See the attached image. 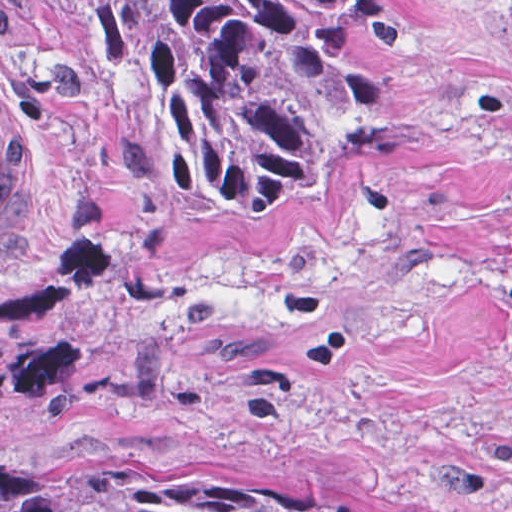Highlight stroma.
Wrapping results in <instances>:
<instances>
[{"mask_svg": "<svg viewBox=\"0 0 512 512\" xmlns=\"http://www.w3.org/2000/svg\"><path fill=\"white\" fill-rule=\"evenodd\" d=\"M394 114L219 214L80 49L0 0L37 177L0 256V512L276 472L354 512H512V0H319Z\"/></svg>", "mask_w": 512, "mask_h": 512, "instance_id": "1", "label": "stroma"}]
</instances>
